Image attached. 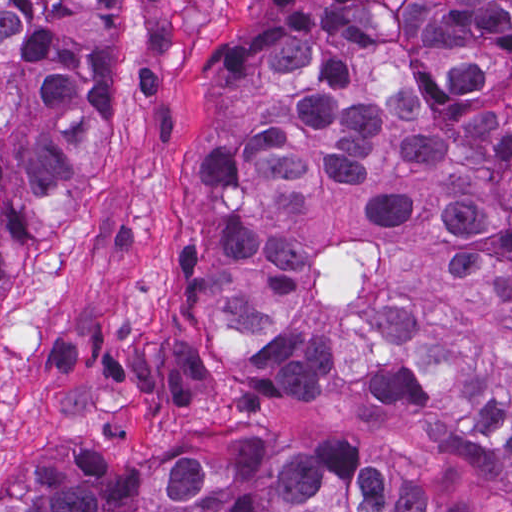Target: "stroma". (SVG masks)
<instances>
[{"label":"stroma","instance_id":"stroma-1","mask_svg":"<svg viewBox=\"0 0 512 512\" xmlns=\"http://www.w3.org/2000/svg\"><path fill=\"white\" fill-rule=\"evenodd\" d=\"M232 2L126 0L121 103L59 214L26 220L0 289V479L14 465L63 475L75 442L143 454L169 414H239L379 448L471 512H512V483L466 477L353 387L317 404L265 398L198 332L205 66ZM506 107L512 117V72Z\"/></svg>","mask_w":512,"mask_h":512}]
</instances>
